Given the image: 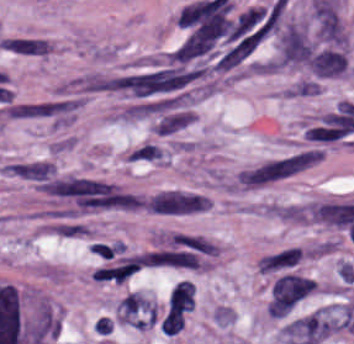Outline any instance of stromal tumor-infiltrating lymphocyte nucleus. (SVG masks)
<instances>
[{"label":"stromal tumor-infiltrating lymphocyte nucleus","instance_id":"1","mask_svg":"<svg viewBox=\"0 0 354 344\" xmlns=\"http://www.w3.org/2000/svg\"><path fill=\"white\" fill-rule=\"evenodd\" d=\"M194 304V283L178 280L174 283L168 298L167 310H192Z\"/></svg>","mask_w":354,"mask_h":344},{"label":"stromal tumor-infiltrating lymphocyte nucleus","instance_id":"2","mask_svg":"<svg viewBox=\"0 0 354 344\" xmlns=\"http://www.w3.org/2000/svg\"><path fill=\"white\" fill-rule=\"evenodd\" d=\"M184 327L183 314L176 307H168L159 329L166 335H174Z\"/></svg>","mask_w":354,"mask_h":344}]
</instances>
